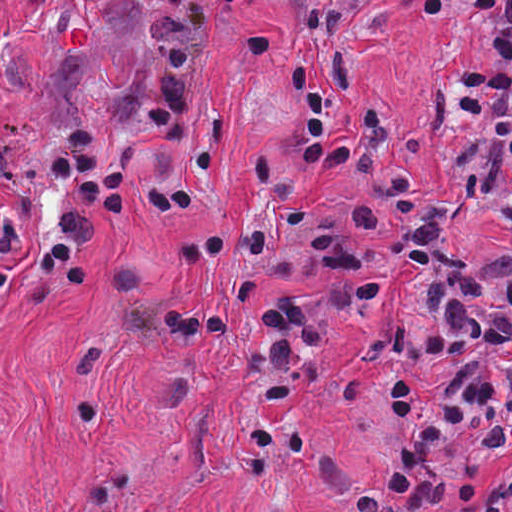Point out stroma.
Instances as JSON below:
<instances>
[{
	"label": "stroma",
	"instance_id": "stroma-1",
	"mask_svg": "<svg viewBox=\"0 0 512 512\" xmlns=\"http://www.w3.org/2000/svg\"><path fill=\"white\" fill-rule=\"evenodd\" d=\"M345 51L399 109L403 153L427 191L446 200L456 246L512 255V231L475 209L441 159L449 93L490 76V39L448 4ZM302 99L297 71L233 100L240 113L220 146L223 182L173 222L143 212L153 187L184 171L183 154L164 131L130 145L127 214L95 247L83 284L22 285L0 305V503L9 512H350L319 477V452L340 456L343 501L375 484L390 444L378 402L382 337L406 303V238L379 181L299 157ZM274 146L291 179L324 200L386 205L388 227L365 236L369 270L324 260L249 187L255 158ZM245 215L310 279L255 273ZM198 222L226 248L196 275L172 262L168 241ZM120 253H145L168 290L227 298L232 321L221 340L136 337L105 309V268ZM280 299L324 308L319 360L299 368V412L259 416L242 389L239 350Z\"/></svg>",
	"mask_w": 512,
	"mask_h": 512
}]
</instances>
